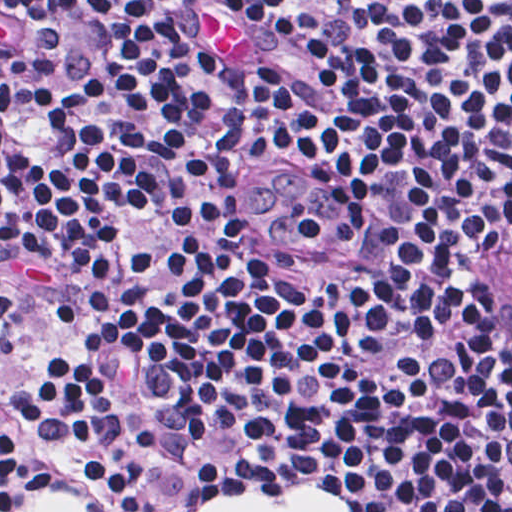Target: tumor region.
I'll use <instances>...</instances> for the list:
<instances>
[{
  "mask_svg": "<svg viewBox=\"0 0 512 512\" xmlns=\"http://www.w3.org/2000/svg\"><path fill=\"white\" fill-rule=\"evenodd\" d=\"M506 249L503 251L502 255L500 256L499 260L497 261L496 265L491 270L485 284L484 289V303L486 305V308L489 312V314L492 316L493 319H495L494 316V289H495V283L497 274L499 271V267L501 265L502 259L505 255Z\"/></svg>",
  "mask_w": 512,
  "mask_h": 512,
  "instance_id": "obj_1",
  "label": "tumor region"
}]
</instances>
